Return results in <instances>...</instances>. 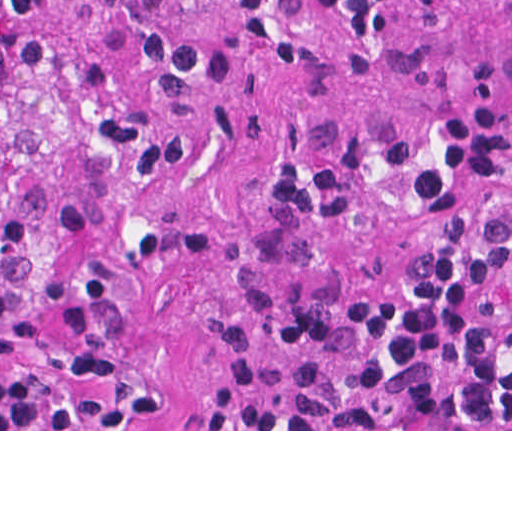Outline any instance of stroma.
<instances>
[{
	"mask_svg": "<svg viewBox=\"0 0 512 512\" xmlns=\"http://www.w3.org/2000/svg\"><path fill=\"white\" fill-rule=\"evenodd\" d=\"M293 40L272 52L221 7L164 269L115 366L63 429L0 431H512L227 429L217 387L241 351L357 313L402 279L430 229L275 221L273 184L382 143L426 139L483 86L512 90V0H417L351 49L313 0H273ZM512 302V245L504 258Z\"/></svg>",
	"mask_w": 512,
	"mask_h": 512,
	"instance_id": "obj_1",
	"label": "stroma"
}]
</instances>
